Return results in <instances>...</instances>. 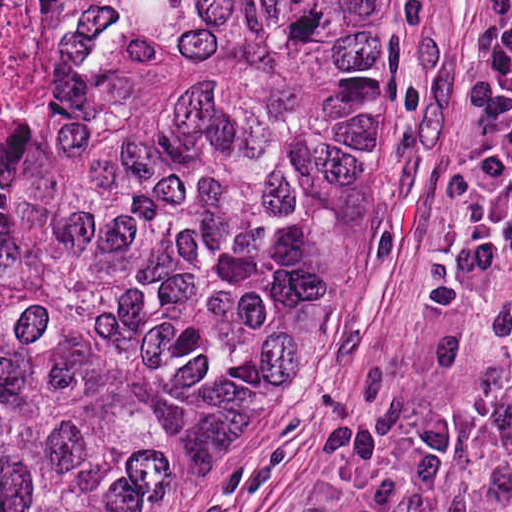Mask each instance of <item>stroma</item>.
<instances>
[{
    "label": "stroma",
    "instance_id": "stroma-1",
    "mask_svg": "<svg viewBox=\"0 0 512 512\" xmlns=\"http://www.w3.org/2000/svg\"><path fill=\"white\" fill-rule=\"evenodd\" d=\"M461 421L439 512H512V0H389V156L281 370L218 412L156 512L369 499L419 420Z\"/></svg>",
    "mask_w": 512,
    "mask_h": 512
}]
</instances>
